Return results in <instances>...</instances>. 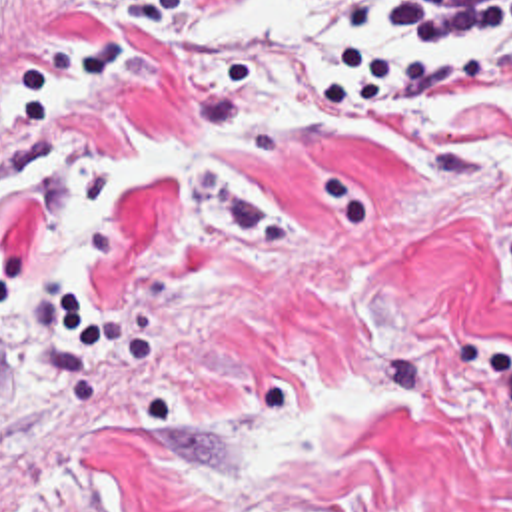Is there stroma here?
<instances>
[{
  "label": "stroma",
  "instance_id": "35a3bbf8",
  "mask_svg": "<svg viewBox=\"0 0 512 512\" xmlns=\"http://www.w3.org/2000/svg\"><path fill=\"white\" fill-rule=\"evenodd\" d=\"M132 3L0 0V512H512V34Z\"/></svg>",
  "mask_w": 512,
  "mask_h": 512
}]
</instances>
